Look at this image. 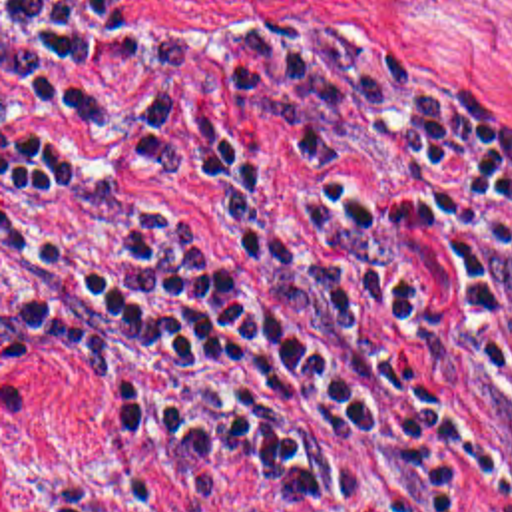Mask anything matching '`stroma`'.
<instances>
[{
  "label": "stroma",
  "mask_w": 512,
  "mask_h": 512,
  "mask_svg": "<svg viewBox=\"0 0 512 512\" xmlns=\"http://www.w3.org/2000/svg\"><path fill=\"white\" fill-rule=\"evenodd\" d=\"M149 25H343L512 127V0H92ZM470 512H504L472 464ZM0 512H271L247 471L143 390L70 364L2 310Z\"/></svg>",
  "instance_id": "obj_1"
}]
</instances>
